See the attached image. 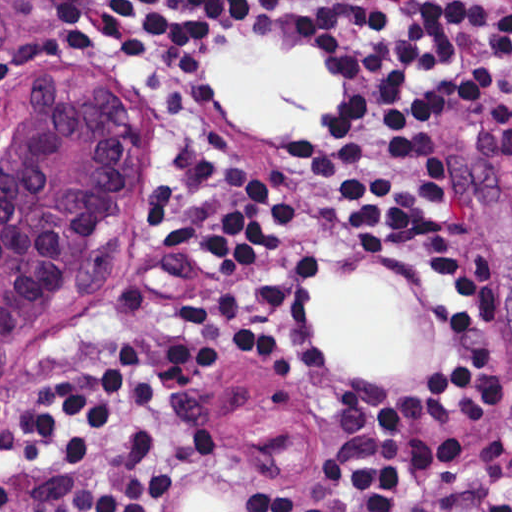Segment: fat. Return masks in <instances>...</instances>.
Returning <instances> with one entry per match:
<instances>
[{"label":"fat","instance_id":"obj_1","mask_svg":"<svg viewBox=\"0 0 512 512\" xmlns=\"http://www.w3.org/2000/svg\"><path fill=\"white\" fill-rule=\"evenodd\" d=\"M211 89L232 113L256 129H307L343 92L323 59L277 42L207 46L203 62ZM384 288L323 292L325 332L358 371H395L410 345V315L377 293Z\"/></svg>","mask_w":512,"mask_h":512}]
</instances>
